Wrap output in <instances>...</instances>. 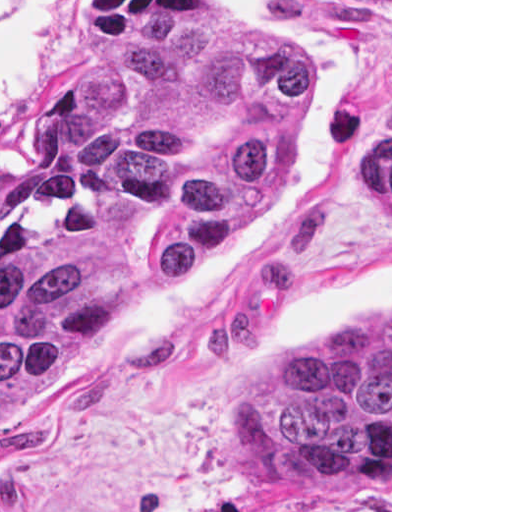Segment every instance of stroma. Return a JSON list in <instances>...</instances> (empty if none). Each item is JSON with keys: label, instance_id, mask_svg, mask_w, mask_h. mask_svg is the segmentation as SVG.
I'll use <instances>...</instances> for the list:
<instances>
[{"label": "stroma", "instance_id": "35a3bbf8", "mask_svg": "<svg viewBox=\"0 0 512 512\" xmlns=\"http://www.w3.org/2000/svg\"><path fill=\"white\" fill-rule=\"evenodd\" d=\"M211 31L296 52L287 143L197 266L0 405V512H392V0H0V212L88 56ZM366 134H390V206L356 178ZM387 313L390 481L267 483L246 454L255 380L320 325Z\"/></svg>", "mask_w": 512, "mask_h": 512}]
</instances>
